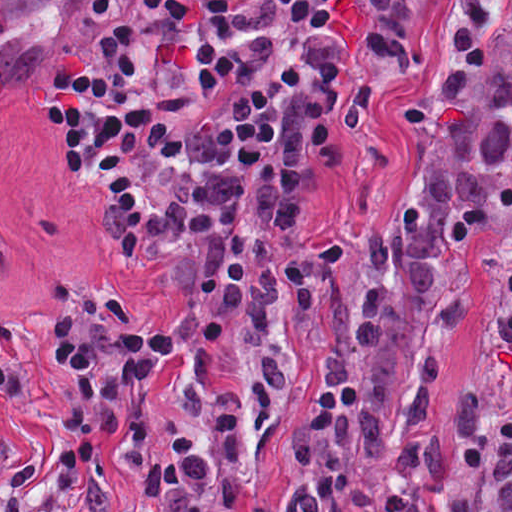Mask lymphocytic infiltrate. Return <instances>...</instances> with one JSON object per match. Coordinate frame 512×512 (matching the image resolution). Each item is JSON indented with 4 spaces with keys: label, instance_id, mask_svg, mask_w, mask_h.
Masks as SVG:
<instances>
[{
    "label": "lymphocytic infiltrate",
    "instance_id": "obj_1",
    "mask_svg": "<svg viewBox=\"0 0 512 512\" xmlns=\"http://www.w3.org/2000/svg\"><path fill=\"white\" fill-rule=\"evenodd\" d=\"M361 0H91L89 43L38 83L50 133L104 201L116 248L140 261L184 235L206 246L201 287L184 314L209 339L264 250L248 189L280 159L284 118L307 85V39ZM53 361L74 400L56 484L77 494L95 440L119 435L142 387L160 380L173 324L91 338L62 287ZM19 366H0V408ZM43 458L25 464L0 512H47L30 495Z\"/></svg>",
    "mask_w": 512,
    "mask_h": 512
}]
</instances>
